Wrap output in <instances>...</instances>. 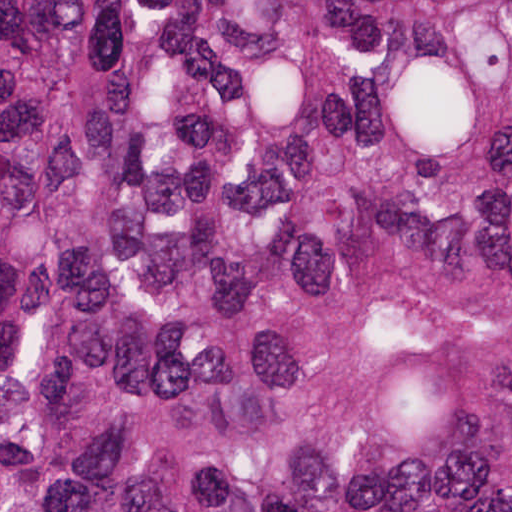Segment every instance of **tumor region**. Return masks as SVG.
Segmentation results:
<instances>
[{
	"instance_id": "tumor-region-1",
	"label": "tumor region",
	"mask_w": 512,
	"mask_h": 512,
	"mask_svg": "<svg viewBox=\"0 0 512 512\" xmlns=\"http://www.w3.org/2000/svg\"><path fill=\"white\" fill-rule=\"evenodd\" d=\"M1 512H512V0H1Z\"/></svg>"
}]
</instances>
